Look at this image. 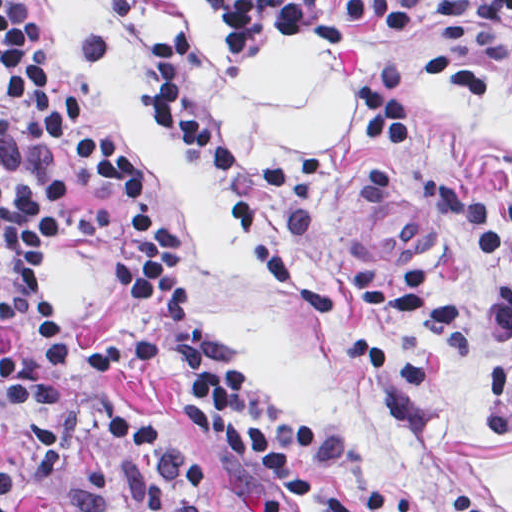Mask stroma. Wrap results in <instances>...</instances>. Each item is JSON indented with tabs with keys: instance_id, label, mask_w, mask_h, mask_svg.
Returning a JSON list of instances; mask_svg holds the SVG:
<instances>
[{
	"instance_id": "obj_1",
	"label": "stroma",
	"mask_w": 512,
	"mask_h": 512,
	"mask_svg": "<svg viewBox=\"0 0 512 512\" xmlns=\"http://www.w3.org/2000/svg\"><path fill=\"white\" fill-rule=\"evenodd\" d=\"M203 1L226 26L230 51L216 65L201 46L183 101L232 150L217 90L276 34L317 42L357 74L358 85L389 60L323 40L307 23L303 0ZM36 2L0 43V67L24 25L40 13L79 116L142 168L130 190H99L76 176L68 191L103 212L150 201L176 275L234 360L284 416L313 436L311 455L302 457L308 475L343 487L358 512H460L449 499L453 489L512 512V437L495 431V375L505 346L488 343L475 358L461 359L401 316L368 311L364 331L434 370L413 419L392 424L375 370L341 330L275 290L226 208L211 165L176 144L163 126L146 80L153 34L183 20L175 0ZM390 60L406 68L413 145L377 148L333 167L311 200L269 201L268 233L297 267L328 280L345 268L404 273L420 265L473 314L490 291L512 286V264L472 253L426 209L414 185L436 182L474 206L512 208V70ZM52 269L70 383L109 394L193 459L215 509L231 512L219 460L180 417L173 377L106 382L89 371V355L105 340L121 299L115 271L70 248L55 253ZM291 509L315 512L295 499ZM14 512L78 511L31 489Z\"/></svg>"
}]
</instances>
